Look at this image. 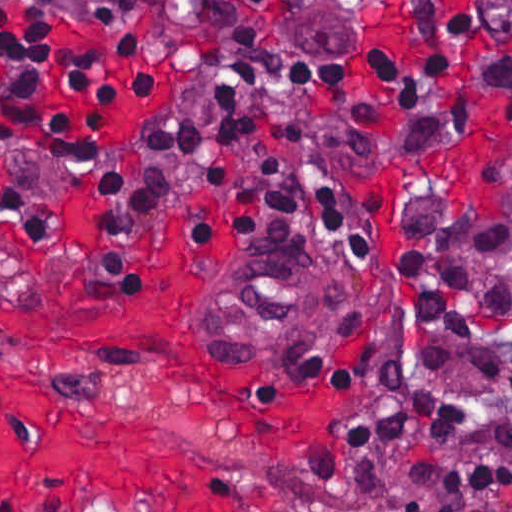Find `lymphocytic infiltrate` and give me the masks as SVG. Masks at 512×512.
Here are the masks:
<instances>
[{
    "label": "lymphocytic infiltrate",
    "instance_id": "obj_1",
    "mask_svg": "<svg viewBox=\"0 0 512 512\" xmlns=\"http://www.w3.org/2000/svg\"><path fill=\"white\" fill-rule=\"evenodd\" d=\"M148 3L218 41L211 82L218 103L206 120H195L184 114L177 97L137 140L110 153L89 186L100 242L85 275L74 276L110 287L139 286L128 257L158 217L180 160L205 145L250 146L259 161L248 169L232 161L210 168L213 179L230 191V203L218 217L194 218V256L223 253L254 230L293 228L326 242L354 289H359L354 281L381 273V206L342 187L314 140L288 119L287 97L306 94L281 60L230 24L169 0H147L144 6ZM140 10L97 32L33 17L0 38V159L26 152L66 171L86 169L115 108L151 96L152 55ZM481 68L487 66L449 49L428 52L324 97L341 110L346 156L374 151L386 90L395 109L417 110L434 100L443 79ZM443 135L416 123L401 159L417 156ZM0 215L12 228L8 243L42 249L60 224L62 209L33 190L6 188ZM394 296L416 349L410 353L420 365L440 368L451 359L447 347L418 343L423 332L437 331L481 347L478 374L512 392V359L485 342L489 332L512 323V193L501 195L493 213L463 191L404 203L396 227ZM467 417L466 403L418 385L394 359L338 421L332 456L315 489L372 504L389 496L402 512H423L425 499L395 502L380 478L381 453L418 439L455 442ZM495 438L512 447V417L495 427ZM411 478L433 492L437 512H470L487 497L512 495V461L491 454L432 456L414 466Z\"/></svg>",
    "mask_w": 512,
    "mask_h": 512
}]
</instances>
